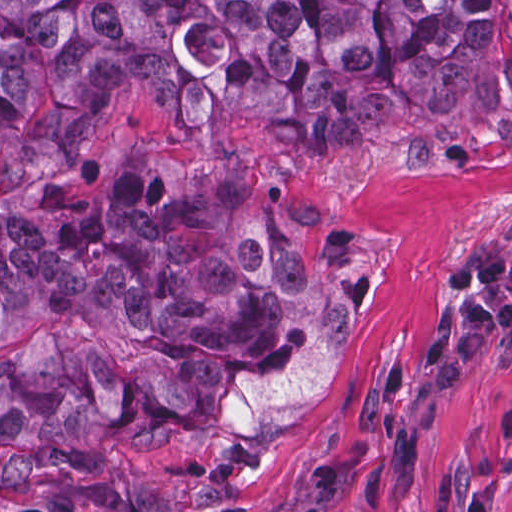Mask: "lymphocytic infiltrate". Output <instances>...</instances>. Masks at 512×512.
I'll return each instance as SVG.
<instances>
[{"label": "lymphocytic infiltrate", "mask_w": 512, "mask_h": 512, "mask_svg": "<svg viewBox=\"0 0 512 512\" xmlns=\"http://www.w3.org/2000/svg\"><path fill=\"white\" fill-rule=\"evenodd\" d=\"M445 284L449 291L464 297L443 309L423 360L437 385H456L482 353L512 334V254L495 243L470 247L447 272ZM345 483L344 466L315 461L307 502L300 512H332ZM15 512L72 509L61 500L55 510L20 507Z\"/></svg>", "instance_id": "1"}]
</instances>
